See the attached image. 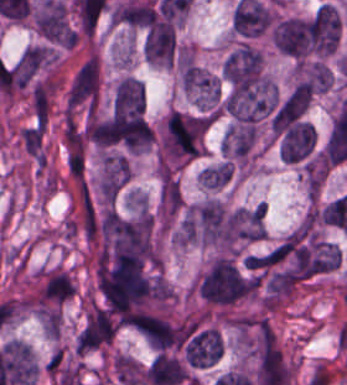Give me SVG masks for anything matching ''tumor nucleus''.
Instances as JSON below:
<instances>
[{"instance_id":"obj_2","label":"tumor nucleus","mask_w":347,"mask_h":385,"mask_svg":"<svg viewBox=\"0 0 347 385\" xmlns=\"http://www.w3.org/2000/svg\"><path fill=\"white\" fill-rule=\"evenodd\" d=\"M192 223L197 238L208 243L230 244L232 216L218 199L206 198L193 209Z\"/></svg>"},{"instance_id":"obj_3","label":"tumor nucleus","mask_w":347,"mask_h":385,"mask_svg":"<svg viewBox=\"0 0 347 385\" xmlns=\"http://www.w3.org/2000/svg\"><path fill=\"white\" fill-rule=\"evenodd\" d=\"M144 57L150 62L170 63L175 51V32L168 21H155L151 23L142 40Z\"/></svg>"},{"instance_id":"obj_6","label":"tumor nucleus","mask_w":347,"mask_h":385,"mask_svg":"<svg viewBox=\"0 0 347 385\" xmlns=\"http://www.w3.org/2000/svg\"><path fill=\"white\" fill-rule=\"evenodd\" d=\"M271 37L278 49L302 55L306 50L305 21L297 16L283 18Z\"/></svg>"},{"instance_id":"obj_4","label":"tumor nucleus","mask_w":347,"mask_h":385,"mask_svg":"<svg viewBox=\"0 0 347 385\" xmlns=\"http://www.w3.org/2000/svg\"><path fill=\"white\" fill-rule=\"evenodd\" d=\"M115 326L109 312L93 307L76 338L77 352L85 351L109 340Z\"/></svg>"},{"instance_id":"obj_5","label":"tumor nucleus","mask_w":347,"mask_h":385,"mask_svg":"<svg viewBox=\"0 0 347 385\" xmlns=\"http://www.w3.org/2000/svg\"><path fill=\"white\" fill-rule=\"evenodd\" d=\"M315 128L308 121L296 120L285 132L279 153L283 160L296 161L307 154L313 145Z\"/></svg>"},{"instance_id":"obj_1","label":"tumor nucleus","mask_w":347,"mask_h":385,"mask_svg":"<svg viewBox=\"0 0 347 385\" xmlns=\"http://www.w3.org/2000/svg\"><path fill=\"white\" fill-rule=\"evenodd\" d=\"M200 290L207 301L228 303L251 290V285L233 260L218 255L201 275Z\"/></svg>"},{"instance_id":"obj_7","label":"tumor nucleus","mask_w":347,"mask_h":385,"mask_svg":"<svg viewBox=\"0 0 347 385\" xmlns=\"http://www.w3.org/2000/svg\"><path fill=\"white\" fill-rule=\"evenodd\" d=\"M200 174L204 187H222L230 179L232 174V165L223 161L218 164L202 168Z\"/></svg>"}]
</instances>
